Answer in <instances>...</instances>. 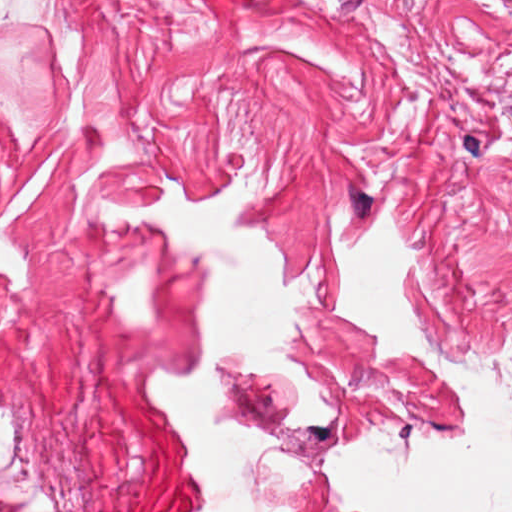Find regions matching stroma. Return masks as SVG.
<instances>
[{
  "label": "stroma",
  "mask_w": 512,
  "mask_h": 512,
  "mask_svg": "<svg viewBox=\"0 0 512 512\" xmlns=\"http://www.w3.org/2000/svg\"><path fill=\"white\" fill-rule=\"evenodd\" d=\"M43 31H0V512H201L148 397L202 371L199 251L101 200H186L246 172L234 218L322 290L296 358L334 416L286 427L289 376L220 359L214 420L304 458L307 504L344 512L337 444L395 459L463 423L436 374L353 330L322 246L336 200L382 202L414 247L399 297L446 360L512 347V0H52Z\"/></svg>",
  "instance_id": "obj_1"
}]
</instances>
